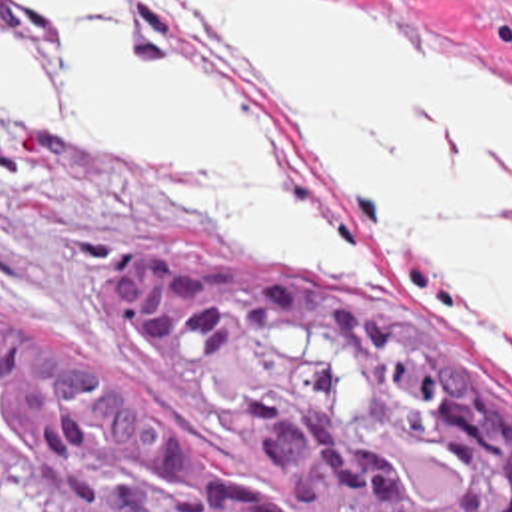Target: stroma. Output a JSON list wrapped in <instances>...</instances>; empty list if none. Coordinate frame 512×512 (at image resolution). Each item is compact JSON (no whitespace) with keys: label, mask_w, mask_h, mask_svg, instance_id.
Returning <instances> with one entry per match:
<instances>
[{"label":"stroma","mask_w":512,"mask_h":512,"mask_svg":"<svg viewBox=\"0 0 512 512\" xmlns=\"http://www.w3.org/2000/svg\"><path fill=\"white\" fill-rule=\"evenodd\" d=\"M339 1L375 15L417 47L479 63L512 85V0ZM0 57L41 119L61 115L59 75L47 47L4 3ZM149 249L315 263L399 303L512 394L511 339L485 315L365 271L333 251L247 239L219 225L161 167L95 157L0 119V305L91 347L259 502L275 512H305L285 462L237 444L233 426L199 388L129 331L119 267Z\"/></svg>","instance_id":"stroma-1"}]
</instances>
